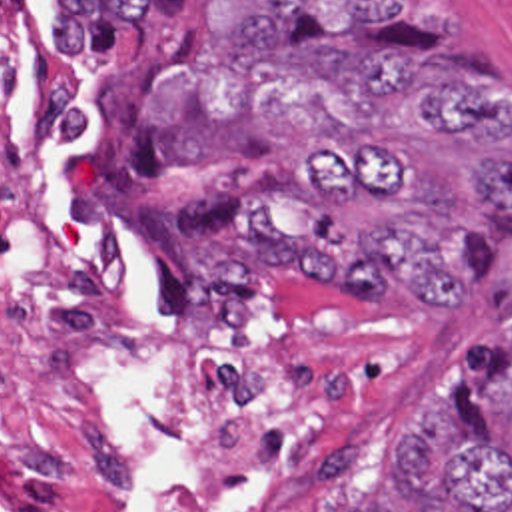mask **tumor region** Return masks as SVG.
I'll return each instance as SVG.
<instances>
[{"mask_svg": "<svg viewBox=\"0 0 512 512\" xmlns=\"http://www.w3.org/2000/svg\"><path fill=\"white\" fill-rule=\"evenodd\" d=\"M58 59L134 49L106 161L138 191L218 179L180 245L184 337L208 378L270 360L268 301L462 309L498 275L466 203L512 227V89L420 49L444 0H52ZM394 444L406 512H512V279Z\"/></svg>", "mask_w": 512, "mask_h": 512, "instance_id": "e687c5a6", "label": "tumor region"}]
</instances>
